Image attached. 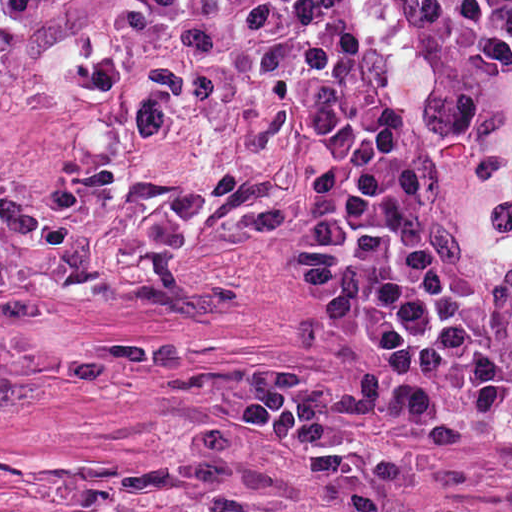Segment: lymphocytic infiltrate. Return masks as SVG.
<instances>
[{"instance_id": "obj_1", "label": "lymphocytic infiltrate", "mask_w": 512, "mask_h": 512, "mask_svg": "<svg viewBox=\"0 0 512 512\" xmlns=\"http://www.w3.org/2000/svg\"><path fill=\"white\" fill-rule=\"evenodd\" d=\"M34 0H0V18ZM508 157V194H426L322 0H97L63 97L255 150L314 188L351 373L234 395L243 435L336 472L432 411H512V0H357Z\"/></svg>"}]
</instances>
